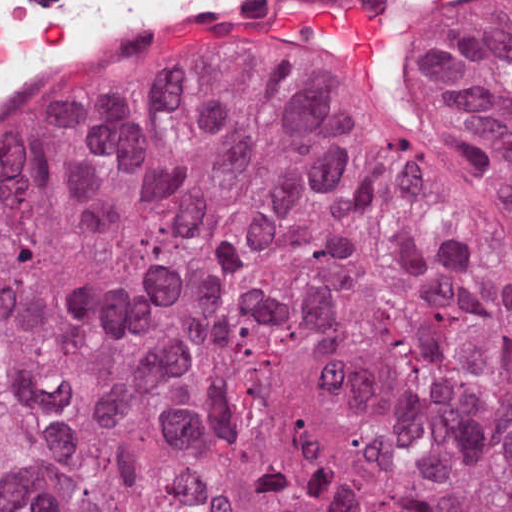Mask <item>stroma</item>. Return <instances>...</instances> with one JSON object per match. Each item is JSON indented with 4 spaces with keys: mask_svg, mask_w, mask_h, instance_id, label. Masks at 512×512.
Listing matches in <instances>:
<instances>
[{
    "mask_svg": "<svg viewBox=\"0 0 512 512\" xmlns=\"http://www.w3.org/2000/svg\"><path fill=\"white\" fill-rule=\"evenodd\" d=\"M453 1L454 0H445L441 4V6L438 8L436 14L433 15L425 33L421 39L419 52H418V56H417V82H418V72L421 68L423 61H424V58L429 49V46L435 36L437 27L441 21L443 14L445 13V11L447 9V7ZM222 49H226V48H194L190 51H217V50H222ZM336 91L345 100L349 101L350 103L357 106L358 108L366 111L367 113H369L383 121H386L390 124H393L395 126H398L402 129H405L409 132H412L416 135H419L421 137H424V138L430 140L429 138H427L425 135H423L417 129L396 121L394 118H392L386 112H384L380 109H377L375 107H372L370 105H367L366 103H363V102H360L353 98H350V97L342 94L338 90H336ZM437 146H439L440 148L447 151L449 154L456 157L467 167L473 169L474 171L478 172L479 174H481L491 180H494L496 182H499V183L507 186L508 188H510L512 190V187L507 183V181L462 136L454 144H437Z\"/></svg>",
    "mask_w": 512,
    "mask_h": 512,
    "instance_id": "35a3bbf8",
    "label": "stroma"
}]
</instances>
